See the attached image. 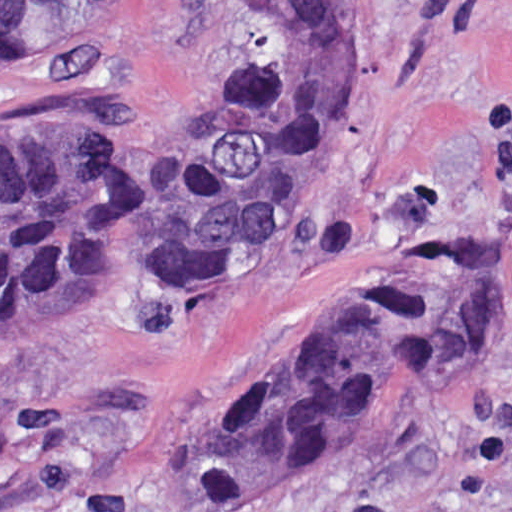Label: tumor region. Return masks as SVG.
Segmentation results:
<instances>
[{
	"label": "tumor region",
	"mask_w": 512,
	"mask_h": 512,
	"mask_svg": "<svg viewBox=\"0 0 512 512\" xmlns=\"http://www.w3.org/2000/svg\"><path fill=\"white\" fill-rule=\"evenodd\" d=\"M130 0H0V57ZM225 97L169 148L0 135V336L85 304H181L237 280L346 145L357 21L379 1H251ZM512 329V280L441 234L211 409L186 460L195 512H269L328 483L412 398Z\"/></svg>",
	"instance_id": "e687c5a6"
}]
</instances>
